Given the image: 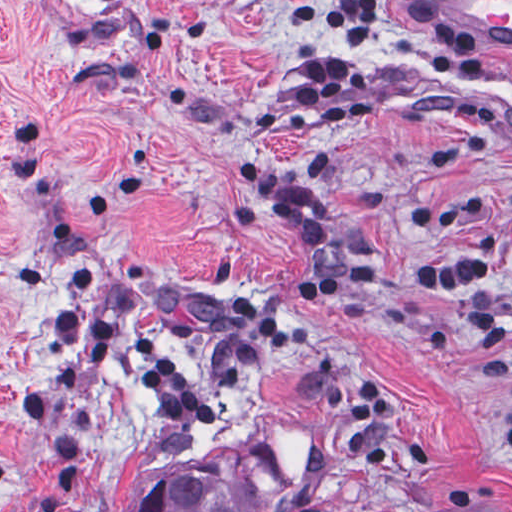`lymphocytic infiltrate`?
<instances>
[{
	"instance_id": "obj_1",
	"label": "lymphocytic infiltrate",
	"mask_w": 512,
	"mask_h": 512,
	"mask_svg": "<svg viewBox=\"0 0 512 512\" xmlns=\"http://www.w3.org/2000/svg\"><path fill=\"white\" fill-rule=\"evenodd\" d=\"M311 28L322 43L342 54L292 64L291 95L322 128H351L370 115V78L349 56H408L432 62L452 78L473 75L483 67L482 55L461 30L420 0H318ZM230 167L241 189L290 224L299 245L313 254L289 287L292 299L318 303L370 280L369 266L339 261L308 187L250 155L237 157ZM504 204L512 213V189L504 193ZM493 271V234L481 230L454 259L409 272V282L431 290H466ZM234 295L242 336L218 368L226 389L246 387L266 360L290 348V333L274 313ZM467 325L483 353L512 343V318L504 320L489 307L468 314ZM57 330L85 361V374L106 371L116 355L143 391L175 388L178 383V368L162 342L123 315L97 312L86 304L71 306L59 315ZM347 412L352 421H394L399 399L380 373H367L351 384Z\"/></svg>"
}]
</instances>
